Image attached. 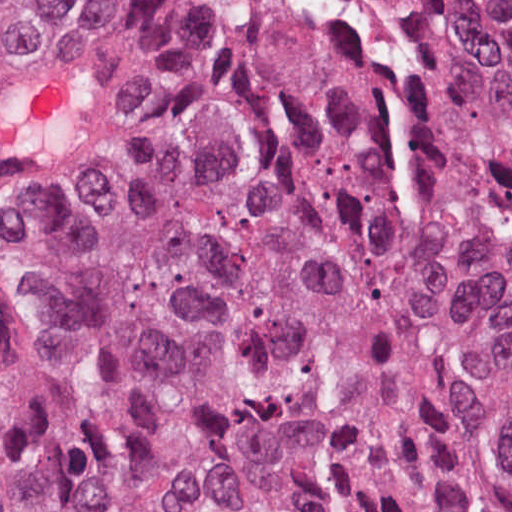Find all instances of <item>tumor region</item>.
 Segmentation results:
<instances>
[{
  "label": "tumor region",
  "mask_w": 512,
  "mask_h": 512,
  "mask_svg": "<svg viewBox=\"0 0 512 512\" xmlns=\"http://www.w3.org/2000/svg\"><path fill=\"white\" fill-rule=\"evenodd\" d=\"M122 70L99 246L0 316V512H512V101L421 0H6Z\"/></svg>",
  "instance_id": "obj_1"
}]
</instances>
